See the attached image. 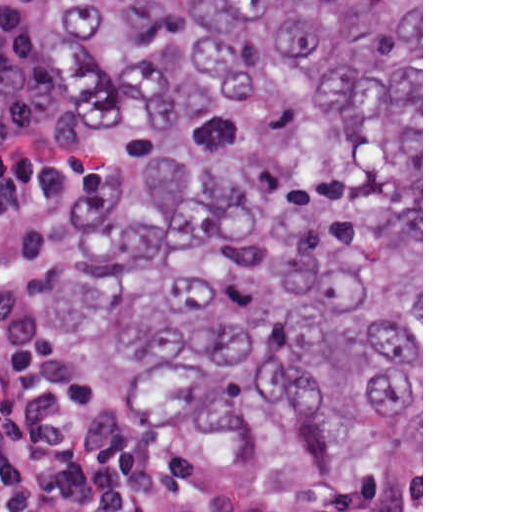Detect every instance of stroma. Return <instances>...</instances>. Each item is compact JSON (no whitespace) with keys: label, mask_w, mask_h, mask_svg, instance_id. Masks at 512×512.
<instances>
[{"label":"stroma","mask_w":512,"mask_h":512,"mask_svg":"<svg viewBox=\"0 0 512 512\" xmlns=\"http://www.w3.org/2000/svg\"><path fill=\"white\" fill-rule=\"evenodd\" d=\"M67 10L68 0H51V65L56 100L86 161L88 186L96 170L91 139L78 89L62 66L59 52V32L65 22ZM0 327L32 355L60 367L101 394L119 400L105 386L86 360L71 349L56 342L21 333L11 328L1 317ZM182 433L194 442L196 448H200L194 439ZM325 490L327 489H300V499ZM394 490L420 507L423 512V0H421V449L410 465L404 488Z\"/></svg>","instance_id":"stroma-1"}]
</instances>
